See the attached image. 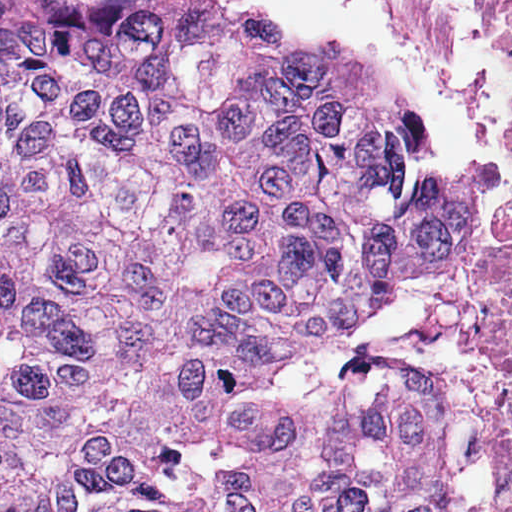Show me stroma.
<instances>
[{
  "mask_svg": "<svg viewBox=\"0 0 512 512\" xmlns=\"http://www.w3.org/2000/svg\"><path fill=\"white\" fill-rule=\"evenodd\" d=\"M512 30V0H483ZM504 210L487 250L430 277H404L358 323L354 343L431 380L441 394V435L457 512H493L501 489L497 442L481 428L473 364L438 342L444 319L512 275V172L501 175Z\"/></svg>",
  "mask_w": 512,
  "mask_h": 512,
  "instance_id": "stroma-1",
  "label": "stroma"
}]
</instances>
